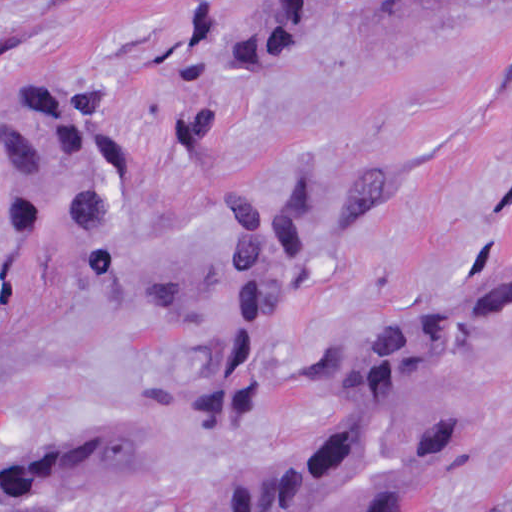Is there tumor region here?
Wrapping results in <instances>:
<instances>
[{
    "label": "tumor region",
    "instance_id": "e687c5a6",
    "mask_svg": "<svg viewBox=\"0 0 512 512\" xmlns=\"http://www.w3.org/2000/svg\"><path fill=\"white\" fill-rule=\"evenodd\" d=\"M438 1L249 0L197 43L220 76L258 77L371 41ZM87 79L20 127L0 213V370L68 319L149 314L190 347L205 423H250L268 326L368 236L393 205L394 177L278 160L190 242L157 249L129 221L126 148ZM509 308L512 200L480 278L331 350L301 391L328 396L317 435L274 468L221 484L193 512H437L483 434L473 346ZM172 461L149 428L90 423L0 454V499L131 494L170 475Z\"/></svg>",
    "mask_w": 512,
    "mask_h": 512
}]
</instances>
